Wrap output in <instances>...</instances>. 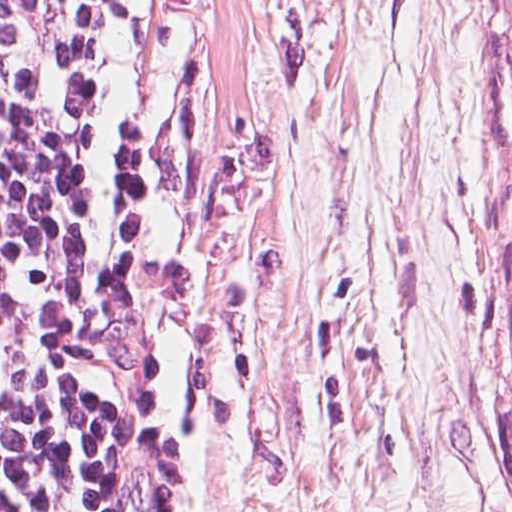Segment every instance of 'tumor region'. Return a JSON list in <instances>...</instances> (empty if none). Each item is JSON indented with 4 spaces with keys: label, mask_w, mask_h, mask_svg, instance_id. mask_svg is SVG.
Here are the masks:
<instances>
[{
    "label": "tumor region",
    "mask_w": 512,
    "mask_h": 512,
    "mask_svg": "<svg viewBox=\"0 0 512 512\" xmlns=\"http://www.w3.org/2000/svg\"><path fill=\"white\" fill-rule=\"evenodd\" d=\"M495 12L498 46L493 107L499 162L507 190L506 230L512 251V0H495Z\"/></svg>",
    "instance_id": "e687c5a6"
}]
</instances>
